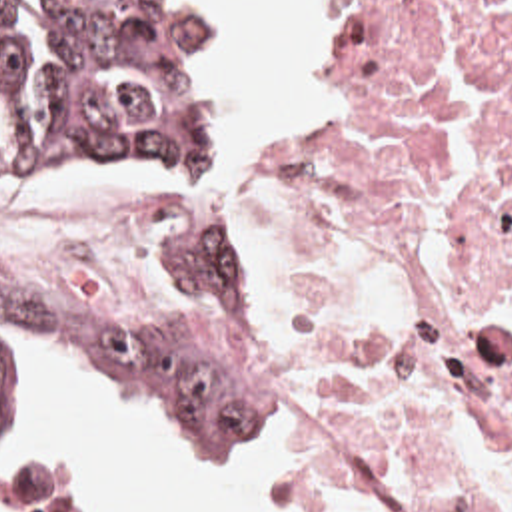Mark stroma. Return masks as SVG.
<instances>
[{"instance_id": "35a3bbf8", "label": "stroma", "mask_w": 512, "mask_h": 512, "mask_svg": "<svg viewBox=\"0 0 512 512\" xmlns=\"http://www.w3.org/2000/svg\"><path fill=\"white\" fill-rule=\"evenodd\" d=\"M178 1L196 39L206 79L210 101V155L192 167L0 171V201H134L122 189H164L190 199V231L200 221L208 225L236 249L254 279V412L250 424L264 414V418H282L296 432V470L280 496L260 512H298L312 488L320 450L312 422L262 374L260 368L256 346V255L262 225L274 195L306 179L334 149L352 85L370 53L372 0H322L318 17V97L308 115L266 129L250 153L226 151L224 69L204 1ZM0 281L28 297L46 299L10 281L2 271ZM172 281L174 251L166 255L146 283L124 299L46 301L150 303ZM20 344L40 348L56 360L80 370L50 346L28 342L0 346V422L10 416L16 400V358ZM110 394L118 402L156 420L176 438L198 450L240 454L252 446L248 428H214L174 420L144 410L114 392ZM8 500L12 512H86L80 496L64 484H20L8 494Z\"/></svg>"}]
</instances>
